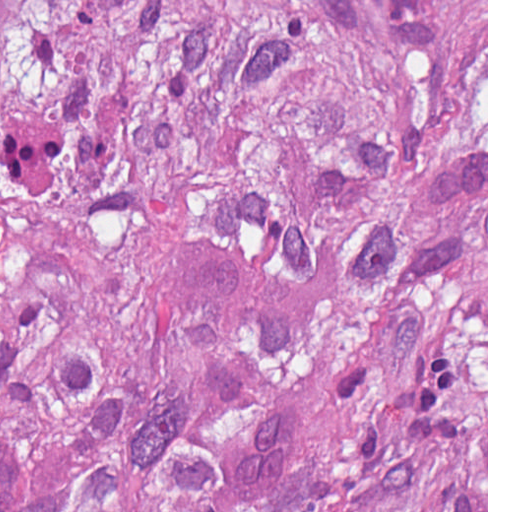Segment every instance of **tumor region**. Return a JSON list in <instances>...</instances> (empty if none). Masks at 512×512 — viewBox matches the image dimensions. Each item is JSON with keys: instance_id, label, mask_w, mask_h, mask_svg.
<instances>
[{"instance_id": "e687c5a6", "label": "tumor region", "mask_w": 512, "mask_h": 512, "mask_svg": "<svg viewBox=\"0 0 512 512\" xmlns=\"http://www.w3.org/2000/svg\"><path fill=\"white\" fill-rule=\"evenodd\" d=\"M0 512H487V0H0Z\"/></svg>"}]
</instances>
